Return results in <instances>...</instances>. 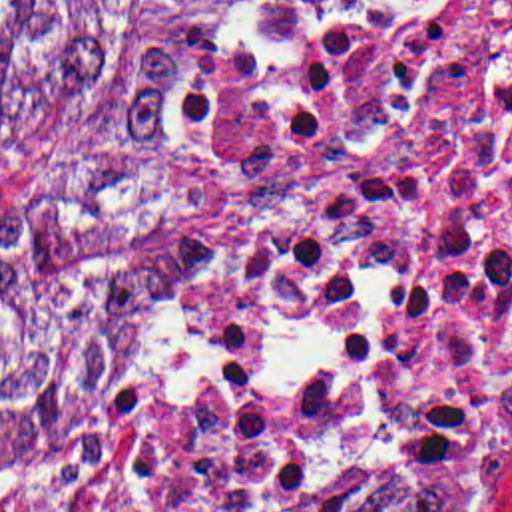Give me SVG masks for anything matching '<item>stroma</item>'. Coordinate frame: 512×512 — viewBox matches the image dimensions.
<instances>
[{"mask_svg":"<svg viewBox=\"0 0 512 512\" xmlns=\"http://www.w3.org/2000/svg\"><path fill=\"white\" fill-rule=\"evenodd\" d=\"M227 298V296H225ZM225 298H223V302H221V306L225 304ZM221 310V308H219ZM490 482L492 480H488V482H484L482 486H478V488H474L472 492H468V494H464L462 498H458V500H454L452 504H456V506H460V512H482V506H484V500H486V494H488V488H490Z\"/></svg>","mask_w":512,"mask_h":512,"instance_id":"stroma-1","label":"stroma"}]
</instances>
